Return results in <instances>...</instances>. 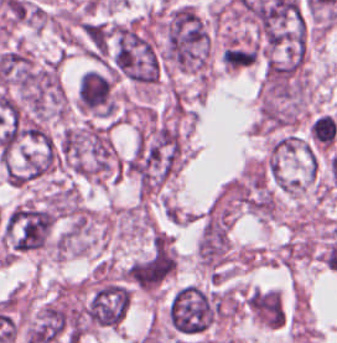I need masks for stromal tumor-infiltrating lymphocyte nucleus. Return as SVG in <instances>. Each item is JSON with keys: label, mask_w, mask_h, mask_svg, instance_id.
Here are the masks:
<instances>
[{"label": "stromal tumor-infiltrating lymphocyte nucleus", "mask_w": 337, "mask_h": 343, "mask_svg": "<svg viewBox=\"0 0 337 343\" xmlns=\"http://www.w3.org/2000/svg\"><path fill=\"white\" fill-rule=\"evenodd\" d=\"M77 97L79 109L105 116L111 111L110 84L95 71L89 70L80 77Z\"/></svg>", "instance_id": "1"}]
</instances>
